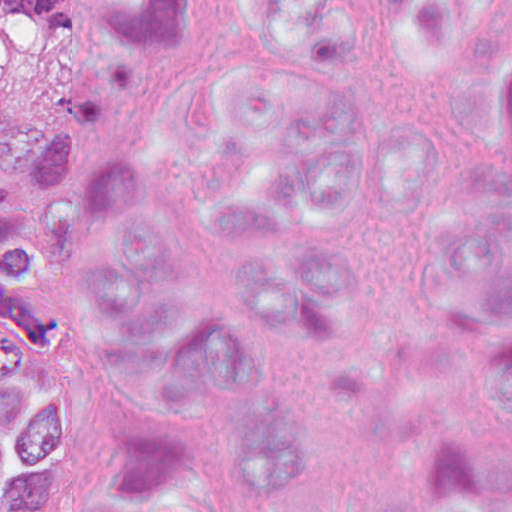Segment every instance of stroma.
Segmentation results:
<instances>
[{
    "instance_id": "1",
    "label": "stroma",
    "mask_w": 512,
    "mask_h": 512,
    "mask_svg": "<svg viewBox=\"0 0 512 512\" xmlns=\"http://www.w3.org/2000/svg\"><path fill=\"white\" fill-rule=\"evenodd\" d=\"M154 51L147 54L143 76L134 94L119 105L99 114L92 133L107 147L123 155V153L147 141L138 137L134 115L143 95L167 82ZM69 261L52 274H35L49 304L68 297ZM0 341H7L0 335ZM9 376L17 377V356L8 372ZM0 512H17L10 505H0Z\"/></svg>"
}]
</instances>
